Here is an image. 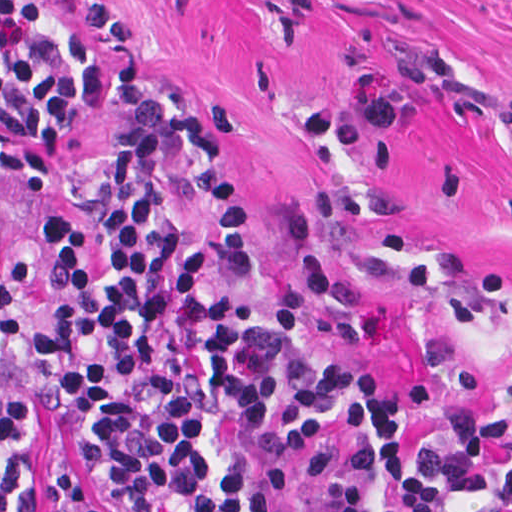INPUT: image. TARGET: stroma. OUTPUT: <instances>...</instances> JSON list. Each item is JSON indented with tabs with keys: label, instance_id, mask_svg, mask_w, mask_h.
Listing matches in <instances>:
<instances>
[{
	"label": "stroma",
	"instance_id": "1",
	"mask_svg": "<svg viewBox=\"0 0 512 512\" xmlns=\"http://www.w3.org/2000/svg\"><path fill=\"white\" fill-rule=\"evenodd\" d=\"M34 1L92 40L108 103L45 182L0 194L11 283L51 288L67 159L179 99L229 147L250 221L251 275L219 283L385 378L425 463L457 434L456 401L512 413V0ZM43 456L108 512L48 413L29 512ZM443 493L442 512H512Z\"/></svg>",
	"mask_w": 512,
	"mask_h": 512
}]
</instances>
